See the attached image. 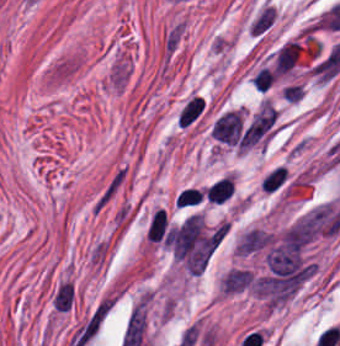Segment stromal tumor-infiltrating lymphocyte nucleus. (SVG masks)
Masks as SVG:
<instances>
[{"instance_id":"obj_1","label":"stromal tumor-infiltrating lymphocyte nucleus","mask_w":340,"mask_h":346,"mask_svg":"<svg viewBox=\"0 0 340 346\" xmlns=\"http://www.w3.org/2000/svg\"><path fill=\"white\" fill-rule=\"evenodd\" d=\"M233 195V182L229 177L217 179L205 189V196L209 202L223 204Z\"/></svg>"},{"instance_id":"obj_2","label":"stromal tumor-infiltrating lymphocyte nucleus","mask_w":340,"mask_h":346,"mask_svg":"<svg viewBox=\"0 0 340 346\" xmlns=\"http://www.w3.org/2000/svg\"><path fill=\"white\" fill-rule=\"evenodd\" d=\"M146 241L167 243V224L164 210L159 208L152 215L147 225Z\"/></svg>"}]
</instances>
